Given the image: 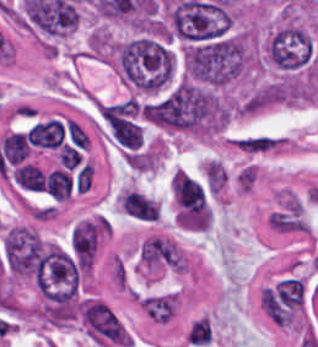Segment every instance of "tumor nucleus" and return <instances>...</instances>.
Wrapping results in <instances>:
<instances>
[{
	"mask_svg": "<svg viewBox=\"0 0 318 347\" xmlns=\"http://www.w3.org/2000/svg\"><path fill=\"white\" fill-rule=\"evenodd\" d=\"M113 63L134 89L155 93L171 82L173 57L158 36L139 35L113 49Z\"/></svg>",
	"mask_w": 318,
	"mask_h": 347,
	"instance_id": "1",
	"label": "tumor nucleus"
},
{
	"mask_svg": "<svg viewBox=\"0 0 318 347\" xmlns=\"http://www.w3.org/2000/svg\"><path fill=\"white\" fill-rule=\"evenodd\" d=\"M247 63V39L227 34L195 41L183 52L184 73L205 85H220L243 74Z\"/></svg>",
	"mask_w": 318,
	"mask_h": 347,
	"instance_id": "2",
	"label": "tumor nucleus"
},
{
	"mask_svg": "<svg viewBox=\"0 0 318 347\" xmlns=\"http://www.w3.org/2000/svg\"><path fill=\"white\" fill-rule=\"evenodd\" d=\"M265 52L280 69L295 70L306 66L310 57V39L303 27L282 22L270 31Z\"/></svg>",
	"mask_w": 318,
	"mask_h": 347,
	"instance_id": "3",
	"label": "tumor nucleus"
},
{
	"mask_svg": "<svg viewBox=\"0 0 318 347\" xmlns=\"http://www.w3.org/2000/svg\"><path fill=\"white\" fill-rule=\"evenodd\" d=\"M138 259L151 271H182V256L177 246L161 238H147L139 246Z\"/></svg>",
	"mask_w": 318,
	"mask_h": 347,
	"instance_id": "4",
	"label": "tumor nucleus"
},
{
	"mask_svg": "<svg viewBox=\"0 0 318 347\" xmlns=\"http://www.w3.org/2000/svg\"><path fill=\"white\" fill-rule=\"evenodd\" d=\"M100 228L101 219H81L72 227L68 237V249L88 267L94 259Z\"/></svg>",
	"mask_w": 318,
	"mask_h": 347,
	"instance_id": "5",
	"label": "tumor nucleus"
}]
</instances>
